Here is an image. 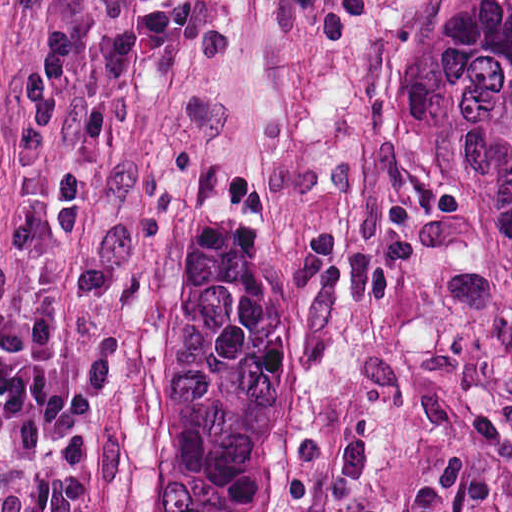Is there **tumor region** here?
I'll return each mask as SVG.
<instances>
[{
  "label": "tumor region",
  "mask_w": 512,
  "mask_h": 512,
  "mask_svg": "<svg viewBox=\"0 0 512 512\" xmlns=\"http://www.w3.org/2000/svg\"><path fill=\"white\" fill-rule=\"evenodd\" d=\"M383 144L512 252V0H421L383 53ZM307 277L188 202L173 247L144 512H287Z\"/></svg>",
  "instance_id": "1"
}]
</instances>
